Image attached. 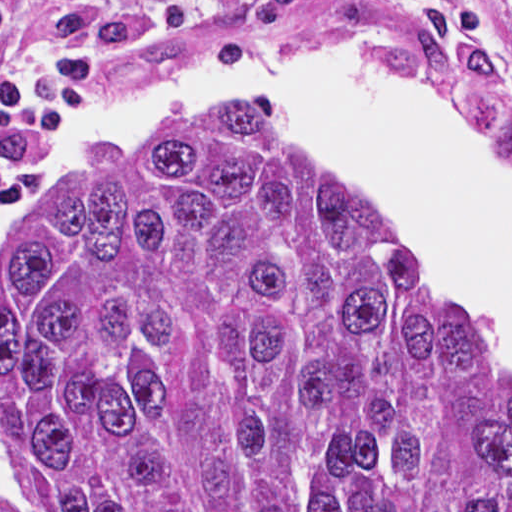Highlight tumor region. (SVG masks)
Segmentation results:
<instances>
[{"label": "tumor region", "mask_w": 512, "mask_h": 512, "mask_svg": "<svg viewBox=\"0 0 512 512\" xmlns=\"http://www.w3.org/2000/svg\"><path fill=\"white\" fill-rule=\"evenodd\" d=\"M249 20L512 88V64L437 9L257 0ZM0 432V512H512V377L442 319L403 235L257 105L86 165L23 227Z\"/></svg>", "instance_id": "e687c5a6"}]
</instances>
